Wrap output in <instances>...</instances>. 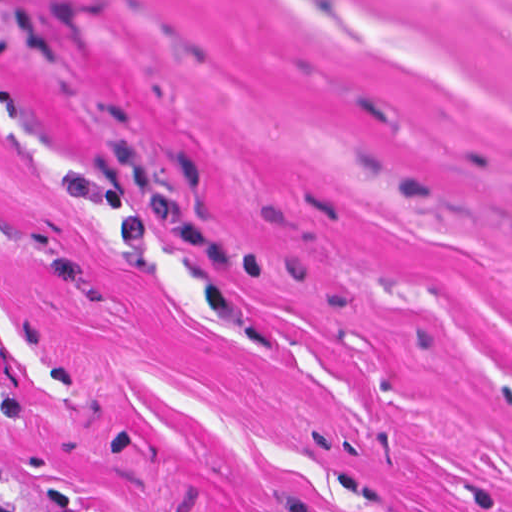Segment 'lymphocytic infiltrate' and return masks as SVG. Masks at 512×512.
I'll return each instance as SVG.
<instances>
[{"label":"lymphocytic infiltrate","mask_w":512,"mask_h":512,"mask_svg":"<svg viewBox=\"0 0 512 512\" xmlns=\"http://www.w3.org/2000/svg\"><path fill=\"white\" fill-rule=\"evenodd\" d=\"M0 512H31L21 505L16 503H11L6 500V498L0 492Z\"/></svg>","instance_id":"lymphocytic-infiltrate-1"}]
</instances>
